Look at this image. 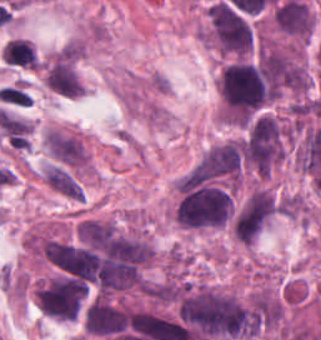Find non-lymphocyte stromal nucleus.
<instances>
[{"label":"non-lymphocyte stromal nucleus","instance_id":"non-lymphocyte-stromal-nucleus-1","mask_svg":"<svg viewBox=\"0 0 321 340\" xmlns=\"http://www.w3.org/2000/svg\"><path fill=\"white\" fill-rule=\"evenodd\" d=\"M42 143L47 157L54 162L75 171L84 167L86 150L80 140L49 128Z\"/></svg>","mask_w":321,"mask_h":340},{"label":"non-lymphocyte stromal nucleus","instance_id":"non-lymphocyte-stromal-nucleus-2","mask_svg":"<svg viewBox=\"0 0 321 340\" xmlns=\"http://www.w3.org/2000/svg\"><path fill=\"white\" fill-rule=\"evenodd\" d=\"M43 179L54 191L72 199L80 200L83 190L75 177L58 163H51L44 167Z\"/></svg>","mask_w":321,"mask_h":340}]
</instances>
